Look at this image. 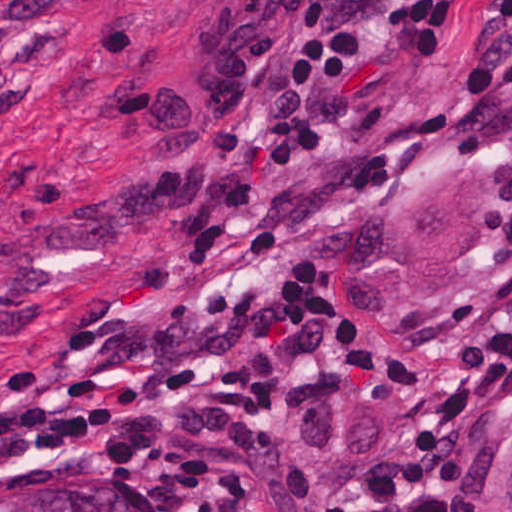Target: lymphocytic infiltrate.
Listing matches in <instances>:
<instances>
[{"label":"lymphocytic infiltrate","instance_id":"1","mask_svg":"<svg viewBox=\"0 0 512 512\" xmlns=\"http://www.w3.org/2000/svg\"><path fill=\"white\" fill-rule=\"evenodd\" d=\"M349 21L362 81L338 141L341 222L425 113L512 64V0H349ZM362 319L383 356L418 383L423 428L397 468L341 512L364 502L406 510L458 484L479 429L512 386V272L420 337Z\"/></svg>","mask_w":512,"mask_h":512}]
</instances>
